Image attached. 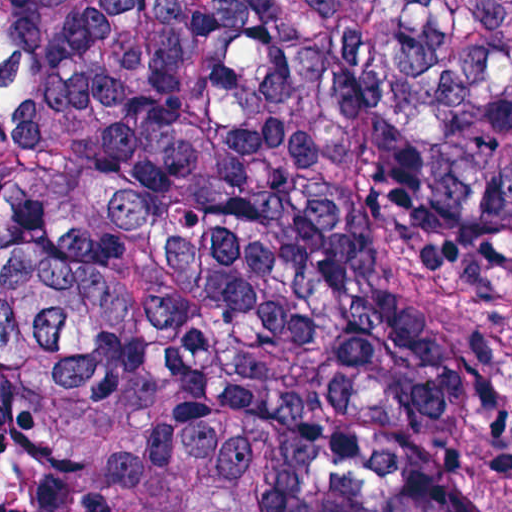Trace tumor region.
<instances>
[{"label":"tumor region","instance_id":"1","mask_svg":"<svg viewBox=\"0 0 512 512\" xmlns=\"http://www.w3.org/2000/svg\"><path fill=\"white\" fill-rule=\"evenodd\" d=\"M0 378L24 512H512V0H105Z\"/></svg>","mask_w":512,"mask_h":512}]
</instances>
